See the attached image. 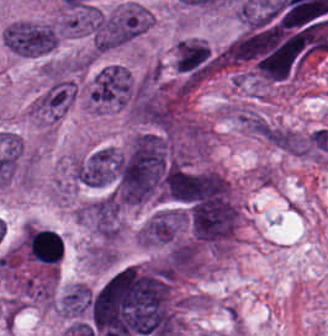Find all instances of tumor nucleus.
<instances>
[{"mask_svg": "<svg viewBox=\"0 0 328 336\" xmlns=\"http://www.w3.org/2000/svg\"><path fill=\"white\" fill-rule=\"evenodd\" d=\"M1 37L13 54L34 58L55 50L60 33L54 22L19 19L9 22Z\"/></svg>", "mask_w": 328, "mask_h": 336, "instance_id": "obj_1", "label": "tumor nucleus"}, {"mask_svg": "<svg viewBox=\"0 0 328 336\" xmlns=\"http://www.w3.org/2000/svg\"><path fill=\"white\" fill-rule=\"evenodd\" d=\"M76 218L99 240L115 243L120 237L119 205L107 193L82 204Z\"/></svg>", "mask_w": 328, "mask_h": 336, "instance_id": "obj_2", "label": "tumor nucleus"}, {"mask_svg": "<svg viewBox=\"0 0 328 336\" xmlns=\"http://www.w3.org/2000/svg\"><path fill=\"white\" fill-rule=\"evenodd\" d=\"M91 288L81 283L66 286L57 299V311L62 318L82 321L89 311Z\"/></svg>", "mask_w": 328, "mask_h": 336, "instance_id": "obj_3", "label": "tumor nucleus"}]
</instances>
